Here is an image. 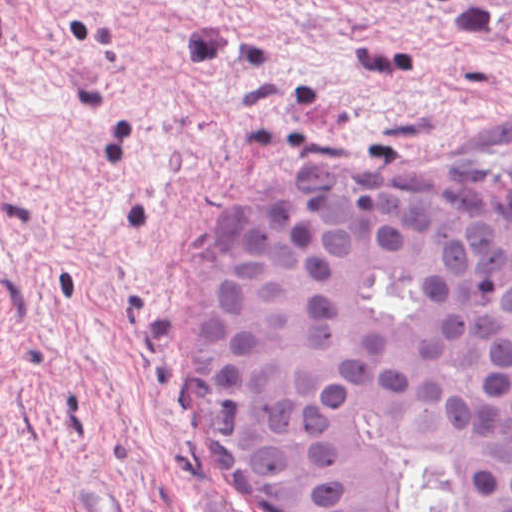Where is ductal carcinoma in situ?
<instances>
[{
    "label": "ductal carcinoma in situ",
    "mask_w": 512,
    "mask_h": 512,
    "mask_svg": "<svg viewBox=\"0 0 512 512\" xmlns=\"http://www.w3.org/2000/svg\"><path fill=\"white\" fill-rule=\"evenodd\" d=\"M227 229L178 364L224 483L270 512H512V205L287 178Z\"/></svg>",
    "instance_id": "ductal-carcinoma-in-situ-1"
}]
</instances>
